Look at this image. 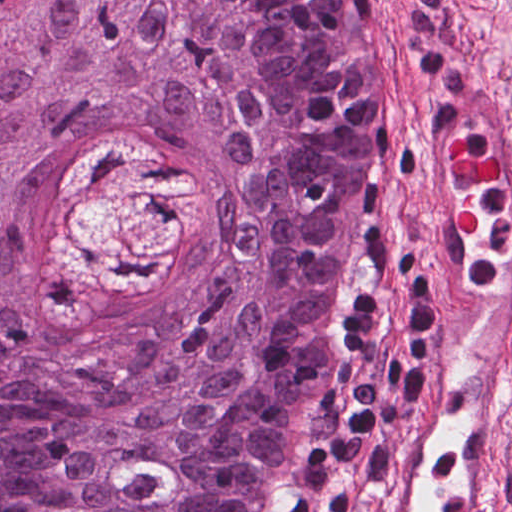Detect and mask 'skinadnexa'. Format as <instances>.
I'll list each match as a JSON object with an SVG mask.
<instances>
[{"label":"skin adnexa","mask_w":512,"mask_h":512,"mask_svg":"<svg viewBox=\"0 0 512 512\" xmlns=\"http://www.w3.org/2000/svg\"><path fill=\"white\" fill-rule=\"evenodd\" d=\"M378 49L372 0H0V512H276Z\"/></svg>","instance_id":"obj_1"}]
</instances>
